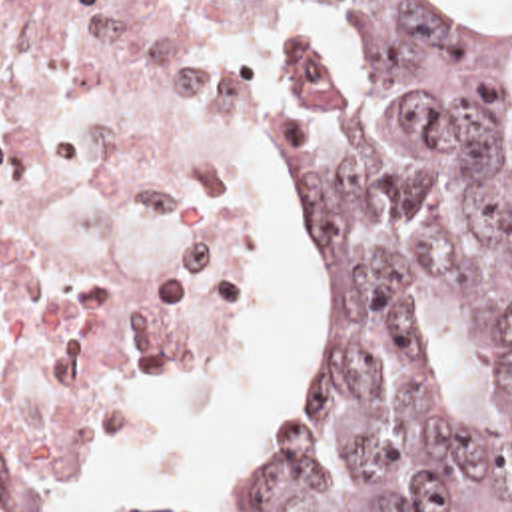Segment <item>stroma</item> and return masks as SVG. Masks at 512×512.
Segmentation results:
<instances>
[{
  "label": "stroma",
  "mask_w": 512,
  "mask_h": 512,
  "mask_svg": "<svg viewBox=\"0 0 512 512\" xmlns=\"http://www.w3.org/2000/svg\"><path fill=\"white\" fill-rule=\"evenodd\" d=\"M239 17L247 43L267 75V127L259 149L239 177V219L247 241L267 271V297L279 311V386L263 422L219 444L239 466L253 462L285 436L303 408V309L283 253L271 231V145L277 123V0H223ZM267 313L261 299L241 334L211 354L167 370L137 372L101 396L53 460L49 512H79L85 462L119 438L161 394L195 380L229 378L263 362ZM119 472L101 494V512L121 498Z\"/></svg>",
  "instance_id": "obj_1"
}]
</instances>
